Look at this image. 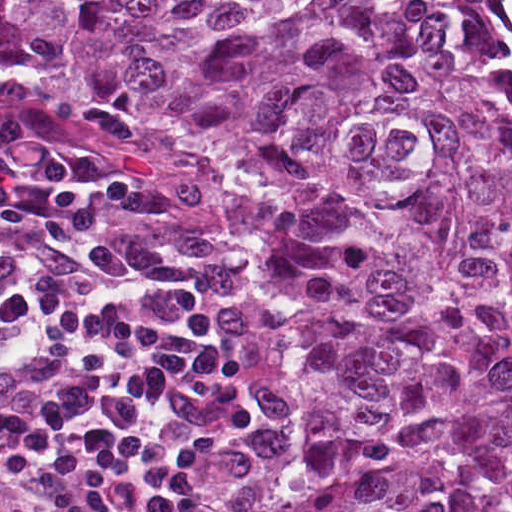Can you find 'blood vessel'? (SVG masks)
<instances>
[{
	"mask_svg": "<svg viewBox=\"0 0 512 512\" xmlns=\"http://www.w3.org/2000/svg\"><path fill=\"white\" fill-rule=\"evenodd\" d=\"M15 98L17 100H20V101H26V102H32V103H53L51 101H48L44 98H41V97H38V96H35V95H32V94H29V93H12ZM46 106H51V107H54L56 109H58L59 111L65 113L66 115L70 116V117H73L70 113H68L65 109H63L62 107L58 106V105H46ZM52 143H56V144H62V145H69V144H65V143H61V142H57V141H50ZM99 157V156H98ZM106 165H108L112 170H114L116 173L120 174V175H123V176H126L130 179H132L133 181H135L136 183H138L139 185H141L142 187H144L146 190H148L146 188V186L138 179L120 171L118 168H116L114 165H112L110 162H108L107 160L99 157ZM149 191V190H148ZM150 192V191H149ZM154 195V194H153ZM154 196H157V195H154Z\"/></svg>",
	"mask_w": 512,
	"mask_h": 512,
	"instance_id": "obj_1",
	"label": "blood vessel"
}]
</instances>
